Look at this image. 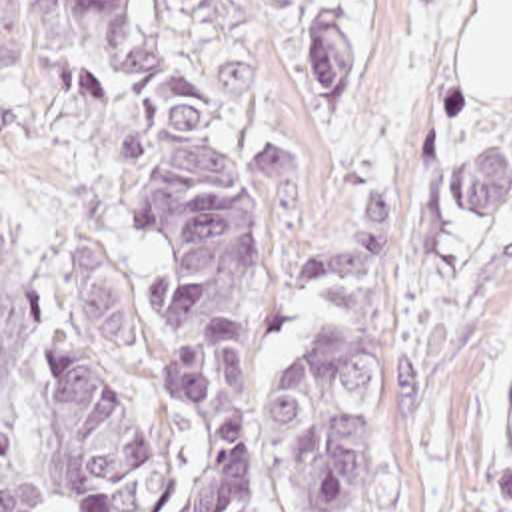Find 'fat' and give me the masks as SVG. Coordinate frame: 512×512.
<instances>
[{
    "instance_id": "1",
    "label": "fat",
    "mask_w": 512,
    "mask_h": 512,
    "mask_svg": "<svg viewBox=\"0 0 512 512\" xmlns=\"http://www.w3.org/2000/svg\"><path fill=\"white\" fill-rule=\"evenodd\" d=\"M475 99H512V0H481L461 71Z\"/></svg>"
}]
</instances>
